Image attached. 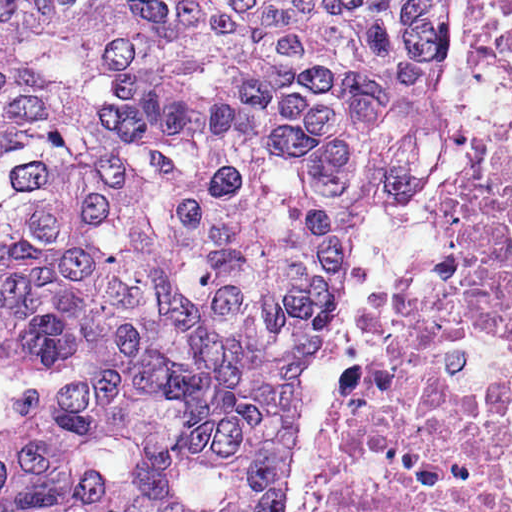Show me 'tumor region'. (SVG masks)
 Wrapping results in <instances>:
<instances>
[{
	"label": "tumor region",
	"mask_w": 512,
	"mask_h": 512,
	"mask_svg": "<svg viewBox=\"0 0 512 512\" xmlns=\"http://www.w3.org/2000/svg\"><path fill=\"white\" fill-rule=\"evenodd\" d=\"M456 65L457 0H0V512H276Z\"/></svg>",
	"instance_id": "e687c5a6"
}]
</instances>
